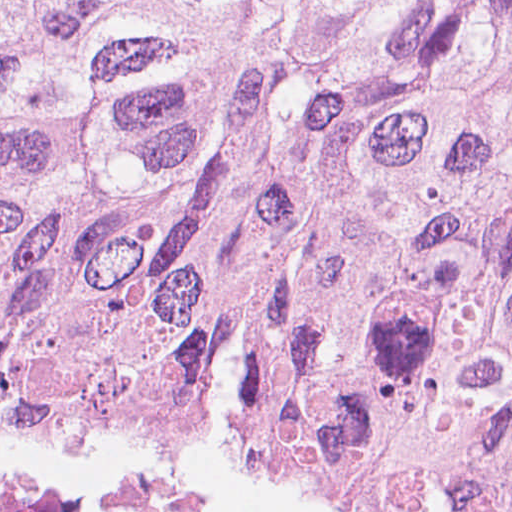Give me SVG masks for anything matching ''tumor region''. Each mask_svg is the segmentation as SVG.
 Masks as SVG:
<instances>
[{
  "label": "tumor region",
  "instance_id": "1",
  "mask_svg": "<svg viewBox=\"0 0 512 512\" xmlns=\"http://www.w3.org/2000/svg\"><path fill=\"white\" fill-rule=\"evenodd\" d=\"M0 441L512 458V0H0Z\"/></svg>",
  "mask_w": 512,
  "mask_h": 512
}]
</instances>
